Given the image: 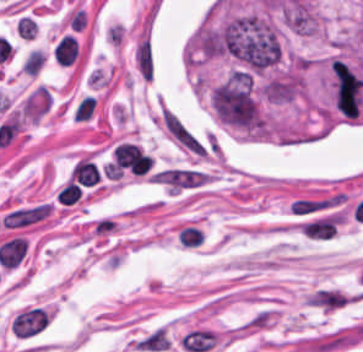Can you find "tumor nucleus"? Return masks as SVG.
I'll return each mask as SVG.
<instances>
[{
    "mask_svg": "<svg viewBox=\"0 0 363 352\" xmlns=\"http://www.w3.org/2000/svg\"><path fill=\"white\" fill-rule=\"evenodd\" d=\"M262 93L269 101L285 104L302 94V77L296 69H289L268 77L262 84Z\"/></svg>",
    "mask_w": 363,
    "mask_h": 352,
    "instance_id": "2f306a5c",
    "label": "tumor nucleus"
}]
</instances>
